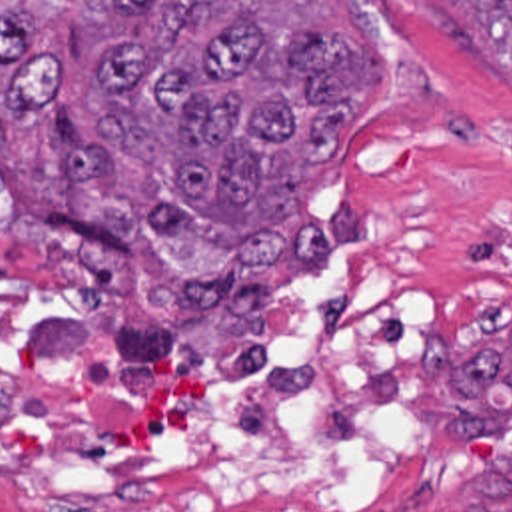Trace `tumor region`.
<instances>
[{
  "instance_id": "e687c5a6",
  "label": "tumor region",
  "mask_w": 512,
  "mask_h": 512,
  "mask_svg": "<svg viewBox=\"0 0 512 512\" xmlns=\"http://www.w3.org/2000/svg\"><path fill=\"white\" fill-rule=\"evenodd\" d=\"M263 0H0V232L105 294L127 270L169 322L225 318L237 352L283 256L353 244L319 228L309 180L375 94V42L265 20ZM512 84V0H457ZM457 421H512V340L447 383ZM483 467L465 512H512Z\"/></svg>"
}]
</instances>
